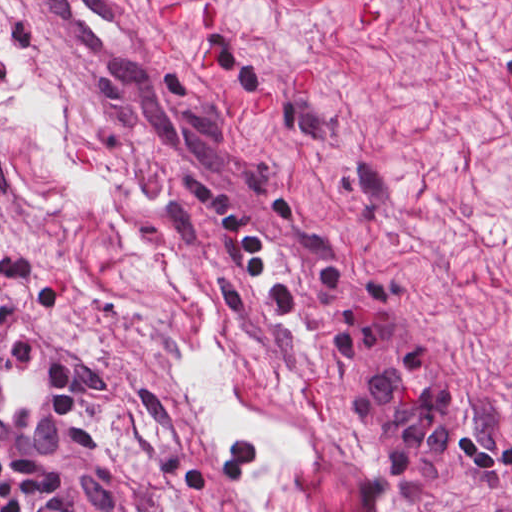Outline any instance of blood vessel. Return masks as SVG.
<instances>
[{
  "mask_svg": "<svg viewBox=\"0 0 512 512\" xmlns=\"http://www.w3.org/2000/svg\"><path fill=\"white\" fill-rule=\"evenodd\" d=\"M75 420L71 363L45 325L11 329L0 340V449L43 454Z\"/></svg>",
  "mask_w": 512,
  "mask_h": 512,
  "instance_id": "8fb6f2fc",
  "label": "blood vessel"
}]
</instances>
